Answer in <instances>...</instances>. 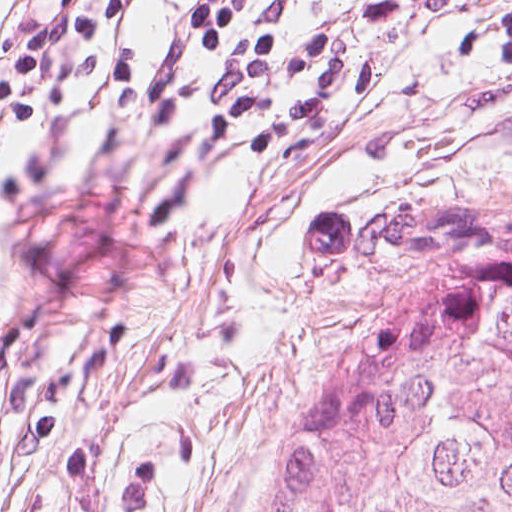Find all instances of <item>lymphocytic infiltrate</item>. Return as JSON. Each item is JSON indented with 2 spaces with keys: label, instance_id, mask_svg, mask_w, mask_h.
Returning <instances> with one entry per match:
<instances>
[{
  "label": "lymphocytic infiltrate",
  "instance_id": "1",
  "mask_svg": "<svg viewBox=\"0 0 512 512\" xmlns=\"http://www.w3.org/2000/svg\"><path fill=\"white\" fill-rule=\"evenodd\" d=\"M394 23L407 0H336ZM166 0H33L0 58V144L41 122L113 117ZM304 0H198L176 122L159 148L152 223L194 243L226 199L374 123L398 97L386 61L327 26ZM461 63L512 69V12L478 27ZM16 268L0 307V405L22 387L21 429L49 440L126 340L127 315L81 330L67 285L61 199L0 219Z\"/></svg>",
  "mask_w": 512,
  "mask_h": 512
}]
</instances>
